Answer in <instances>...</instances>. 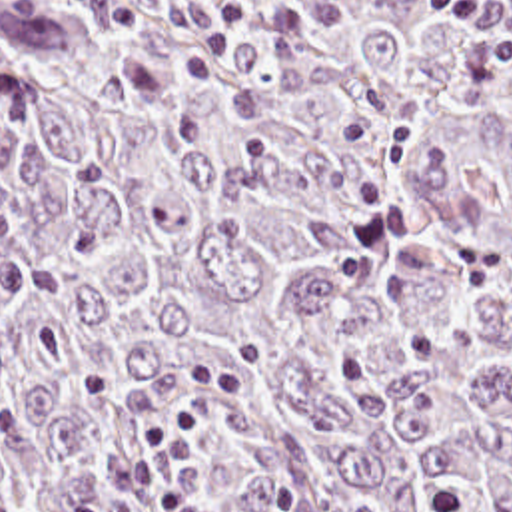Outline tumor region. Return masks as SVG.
<instances>
[{
	"mask_svg": "<svg viewBox=\"0 0 512 512\" xmlns=\"http://www.w3.org/2000/svg\"><path fill=\"white\" fill-rule=\"evenodd\" d=\"M0 512H512V75L431 0H0Z\"/></svg>",
	"mask_w": 512,
	"mask_h": 512,
	"instance_id": "tumor-region-1",
	"label": "tumor region"
}]
</instances>
